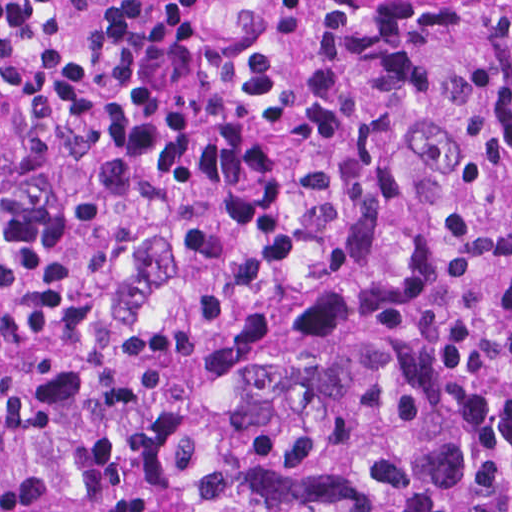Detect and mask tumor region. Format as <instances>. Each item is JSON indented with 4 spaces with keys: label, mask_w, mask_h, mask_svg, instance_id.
I'll return each instance as SVG.
<instances>
[{
    "label": "tumor region",
    "mask_w": 512,
    "mask_h": 512,
    "mask_svg": "<svg viewBox=\"0 0 512 512\" xmlns=\"http://www.w3.org/2000/svg\"><path fill=\"white\" fill-rule=\"evenodd\" d=\"M377 246L0 333V512H512V2L422 64Z\"/></svg>",
    "instance_id": "obj_1"
}]
</instances>
